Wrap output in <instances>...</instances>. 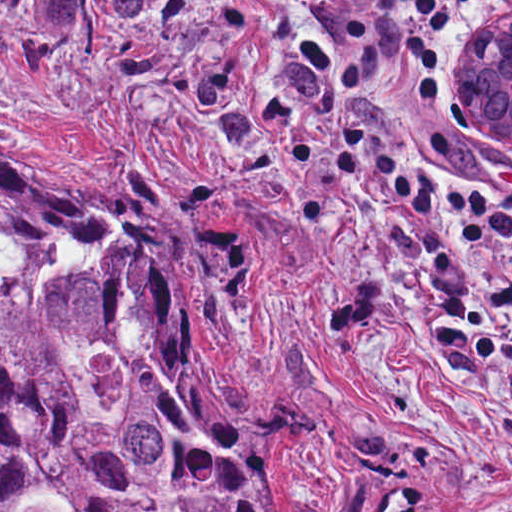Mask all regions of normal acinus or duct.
Returning a JSON list of instances; mask_svg holds the SVG:
<instances>
[{"instance_id":"obj_1","label":"normal acinus or duct","mask_w":512,"mask_h":512,"mask_svg":"<svg viewBox=\"0 0 512 512\" xmlns=\"http://www.w3.org/2000/svg\"><path fill=\"white\" fill-rule=\"evenodd\" d=\"M465 109L474 129L512 137V7L465 59Z\"/></svg>"}]
</instances>
